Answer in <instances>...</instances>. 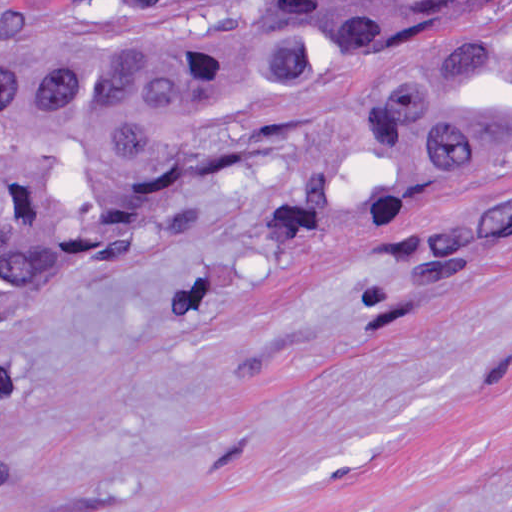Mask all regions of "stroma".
<instances>
[{
  "label": "stroma",
  "mask_w": 512,
  "mask_h": 512,
  "mask_svg": "<svg viewBox=\"0 0 512 512\" xmlns=\"http://www.w3.org/2000/svg\"><path fill=\"white\" fill-rule=\"evenodd\" d=\"M509 185L232 174L0 316V512H512V228L422 239Z\"/></svg>",
  "instance_id": "35a3bbf8"
}]
</instances>
